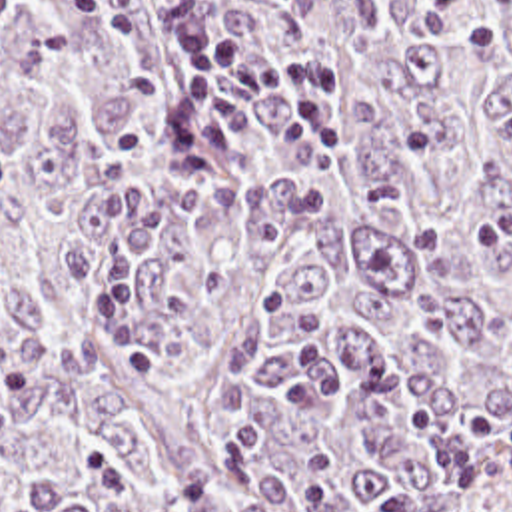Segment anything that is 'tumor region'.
<instances>
[{
	"label": "tumor region",
	"mask_w": 512,
	"mask_h": 512,
	"mask_svg": "<svg viewBox=\"0 0 512 512\" xmlns=\"http://www.w3.org/2000/svg\"><path fill=\"white\" fill-rule=\"evenodd\" d=\"M325 68L179 170L145 0H0V512H512V0H185Z\"/></svg>",
	"instance_id": "obj_1"
}]
</instances>
